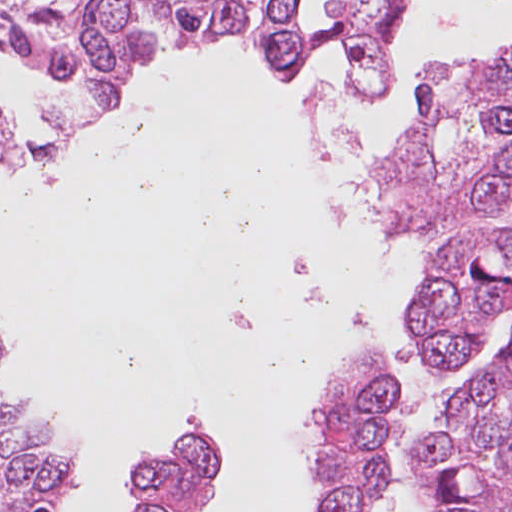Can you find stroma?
<instances>
[{"mask_svg": "<svg viewBox=\"0 0 512 512\" xmlns=\"http://www.w3.org/2000/svg\"><path fill=\"white\" fill-rule=\"evenodd\" d=\"M234 2H235V7L237 10V13L241 20V31L235 36V38L224 40L218 44L205 46V47H202V48H199L194 51L188 52L186 54L178 55V56L204 54V53L223 49L226 46L230 45L231 43L235 42L238 39V37L241 35V33L243 32L244 18H243V11H242V6H241L240 0H234ZM300 13H301L302 17L304 18V20L307 23H309L312 27L323 29L330 25L328 23L318 22V21L310 18L303 8L302 0H300ZM347 16L350 19V21L353 23V25L357 31V26H358L359 21L357 20V18L354 15H347ZM330 45L331 44L322 47L317 53L327 49ZM506 55H512V45L507 50H505L503 53L498 55L497 57L506 56ZM388 59H389V53H387L386 66L388 63ZM24 64H26L32 68H35L37 70H40V71L64 78V79H68L71 81V83L75 87L76 97L71 104L70 115L75 110H78L80 108V106L83 104V102L85 101V91H84L81 83L78 82L77 80L73 79L72 77H70L68 74H66L61 69L51 67L45 63H24ZM304 66L301 67L297 76H299V74L302 71ZM0 106H1L2 110H4V112L7 114L11 123L18 128L19 132L24 137V159H25L26 154H27V148H26V137H25V130H24L23 122L15 113H13L11 110H8L2 103H0ZM119 114L116 115L111 121L107 122L106 124L96 128V129H108L110 126L113 125V123L119 117ZM3 166H10V165H0V167H3ZM413 232L415 235L421 234V233H418L417 231H415L414 229H413Z\"/></svg>", "mask_w": 512, "mask_h": 512, "instance_id": "stroma-1", "label": "stroma"}]
</instances>
